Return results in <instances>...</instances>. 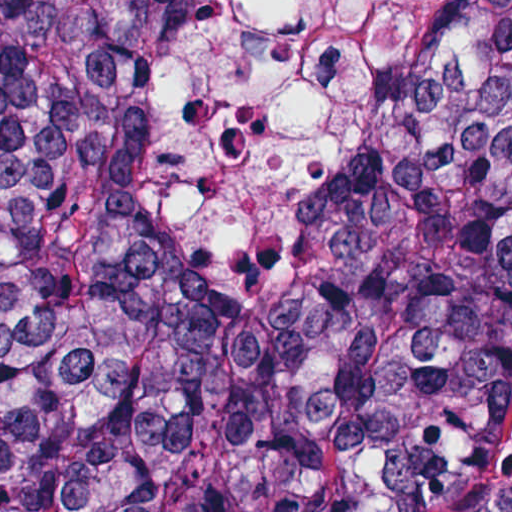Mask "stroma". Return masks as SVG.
<instances>
[{
    "label": "stroma",
    "mask_w": 512,
    "mask_h": 512,
    "mask_svg": "<svg viewBox=\"0 0 512 512\" xmlns=\"http://www.w3.org/2000/svg\"><path fill=\"white\" fill-rule=\"evenodd\" d=\"M4 2L5 0H0V27ZM510 486H512V402L505 416L501 434V451L497 461L485 477L446 512H472Z\"/></svg>",
    "instance_id": "obj_1"
}]
</instances>
